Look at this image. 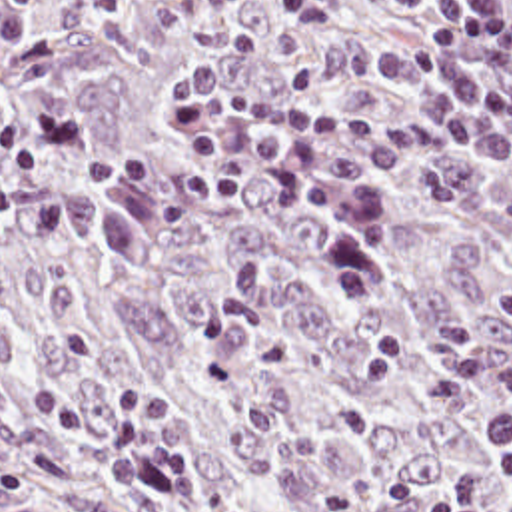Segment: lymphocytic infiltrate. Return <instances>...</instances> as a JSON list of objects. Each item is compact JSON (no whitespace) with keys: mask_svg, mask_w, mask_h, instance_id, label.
<instances>
[{"mask_svg":"<svg viewBox=\"0 0 512 512\" xmlns=\"http://www.w3.org/2000/svg\"><path fill=\"white\" fill-rule=\"evenodd\" d=\"M50 0H0V40H30L34 16ZM225 6H269L297 20L341 14V0H219ZM503 54L512 66V0H441L421 40L391 50L375 64L403 92L415 96L425 132L449 150L495 170L512 172V100L497 90L483 60ZM175 116L199 148L201 164L183 196L197 204H229L241 196L253 162L255 140L235 124L251 116L285 142L299 176L303 204L337 220L331 240L333 278L343 306H359L377 286L379 218L371 176L363 162L321 152L327 144L357 142L361 128L327 108H299L267 90L237 82L215 60L193 62L173 96ZM501 463L512 491V408L489 414L477 431ZM431 512H512L493 503L479 475L465 473Z\"/></svg>","mask_w":512,"mask_h":512,"instance_id":"lymphocytic-infiltrate-1","label":"lymphocytic infiltrate"}]
</instances>
